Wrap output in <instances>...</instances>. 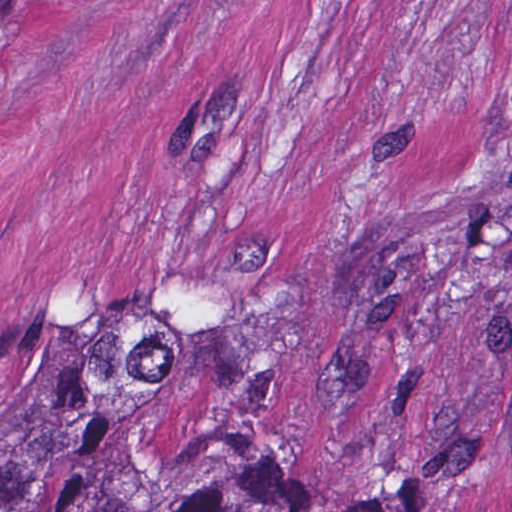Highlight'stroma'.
<instances>
[{
    "label": "stroma",
    "mask_w": 512,
    "mask_h": 512,
    "mask_svg": "<svg viewBox=\"0 0 512 512\" xmlns=\"http://www.w3.org/2000/svg\"><path fill=\"white\" fill-rule=\"evenodd\" d=\"M298 512H512V0H34L0 23V437Z\"/></svg>",
    "instance_id": "obj_1"
}]
</instances>
